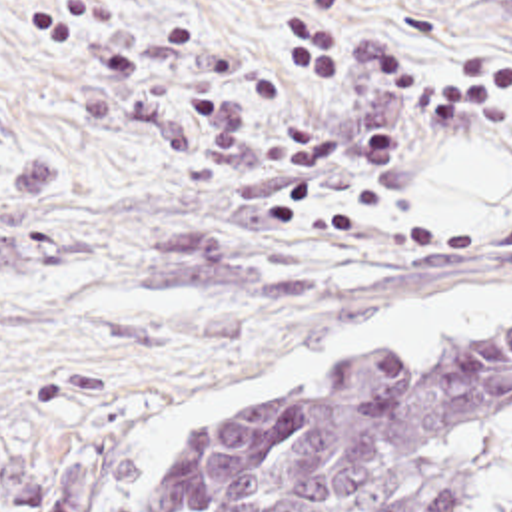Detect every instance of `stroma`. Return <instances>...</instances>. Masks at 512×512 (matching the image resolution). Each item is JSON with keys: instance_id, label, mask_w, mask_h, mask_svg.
Listing matches in <instances>:
<instances>
[{"instance_id": "1", "label": "stroma", "mask_w": 512, "mask_h": 512, "mask_svg": "<svg viewBox=\"0 0 512 512\" xmlns=\"http://www.w3.org/2000/svg\"><path fill=\"white\" fill-rule=\"evenodd\" d=\"M423 79L512 55V0H345ZM284 0H0V512H154L260 396L435 357L507 317L256 386L174 452L126 448L160 404L397 297L512 281V195L425 231L421 167L497 145L512 107L419 123L294 93Z\"/></svg>"}]
</instances>
